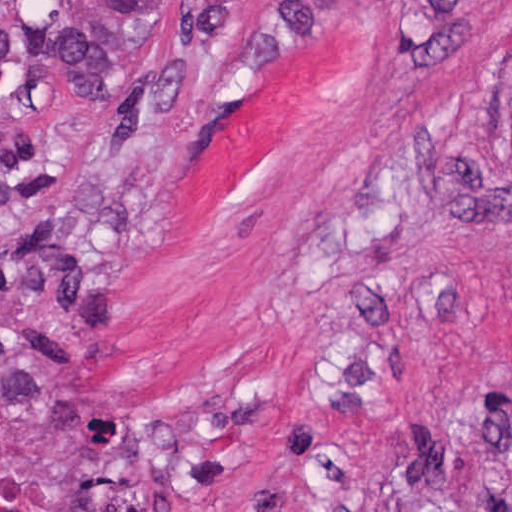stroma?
<instances>
[{"label":"stroma","instance_id":"stroma-1","mask_svg":"<svg viewBox=\"0 0 512 512\" xmlns=\"http://www.w3.org/2000/svg\"><path fill=\"white\" fill-rule=\"evenodd\" d=\"M510 492L512 0H0V512Z\"/></svg>","mask_w":512,"mask_h":512}]
</instances>
